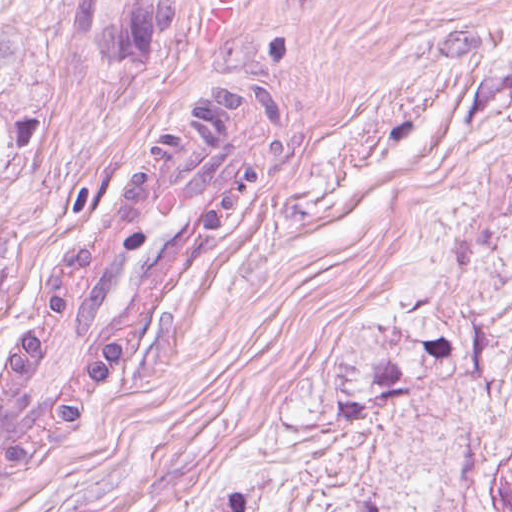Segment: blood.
Masks as SVG:
<instances>
[{"mask_svg": "<svg viewBox=\"0 0 512 512\" xmlns=\"http://www.w3.org/2000/svg\"><path fill=\"white\" fill-rule=\"evenodd\" d=\"M206 12L201 25V37L203 42H213L232 15V0H216Z\"/></svg>", "mask_w": 512, "mask_h": 512, "instance_id": "1", "label": "blood"}]
</instances>
